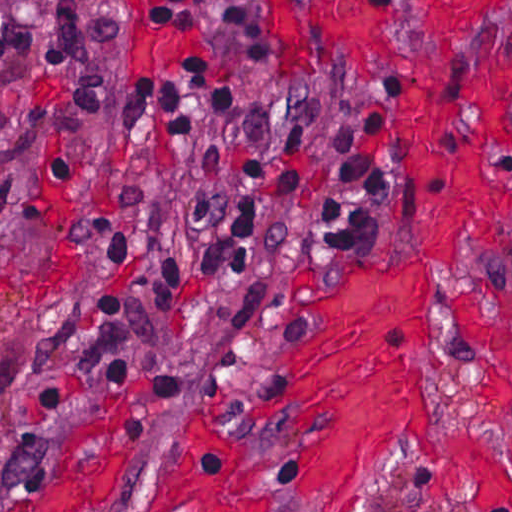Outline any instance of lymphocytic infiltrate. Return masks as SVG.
Returning a JSON list of instances; mask_svg holds the SVG:
<instances>
[{
	"label": "lymphocytic infiltrate",
	"mask_w": 512,
	"mask_h": 512,
	"mask_svg": "<svg viewBox=\"0 0 512 512\" xmlns=\"http://www.w3.org/2000/svg\"><path fill=\"white\" fill-rule=\"evenodd\" d=\"M186 6L187 0H155L153 14L168 18ZM122 106L129 119L154 109L162 131L194 139L208 118L238 112L241 94L199 66L160 90H127ZM376 217L370 159L353 151L276 171L241 188L208 235L152 264L149 317L133 349V372L153 377L183 359L193 341L197 309L213 293L265 262H285L294 244L359 228L357 233L372 228ZM35 472L0 471V512L19 502Z\"/></svg>",
	"instance_id": "obj_1"
}]
</instances>
